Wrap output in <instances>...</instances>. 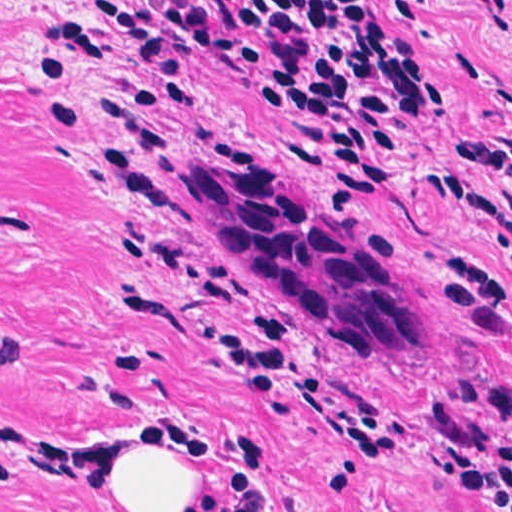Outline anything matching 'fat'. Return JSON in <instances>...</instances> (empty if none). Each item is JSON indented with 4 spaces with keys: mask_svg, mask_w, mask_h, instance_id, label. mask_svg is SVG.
Returning a JSON list of instances; mask_svg holds the SVG:
<instances>
[{
    "mask_svg": "<svg viewBox=\"0 0 512 512\" xmlns=\"http://www.w3.org/2000/svg\"><path fill=\"white\" fill-rule=\"evenodd\" d=\"M203 444L158 446L125 441L94 482L105 512H195Z\"/></svg>",
    "mask_w": 512,
    "mask_h": 512,
    "instance_id": "obj_1",
    "label": "fat"
}]
</instances>
